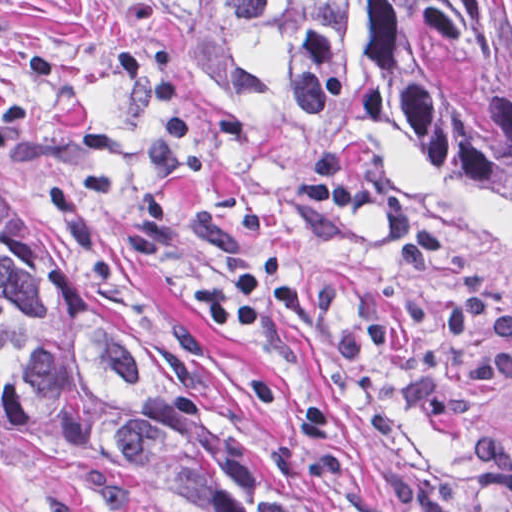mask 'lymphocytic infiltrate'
Segmentation results:
<instances>
[{
	"mask_svg": "<svg viewBox=\"0 0 512 512\" xmlns=\"http://www.w3.org/2000/svg\"><path fill=\"white\" fill-rule=\"evenodd\" d=\"M290 190L298 200L321 209L332 204L373 211L385 223L394 250L409 271L434 266L456 276L460 291L451 300L447 330L460 335L480 329L489 336L486 345L473 346L466 355V384L485 386L497 379L512 384V308L481 269L461 261L438 232L417 221L407 200L352 178L345 151L334 145L319 147L306 157ZM311 308L309 289L288 273L278 252L263 253L247 268L233 271L226 287L212 290L202 304L214 329H254L275 309L302 316ZM470 463L480 499L512 510V436L475 434Z\"/></svg>",
	"mask_w": 512,
	"mask_h": 512,
	"instance_id": "f902f5d3",
	"label": "lymphocytic infiltrate"
}]
</instances>
